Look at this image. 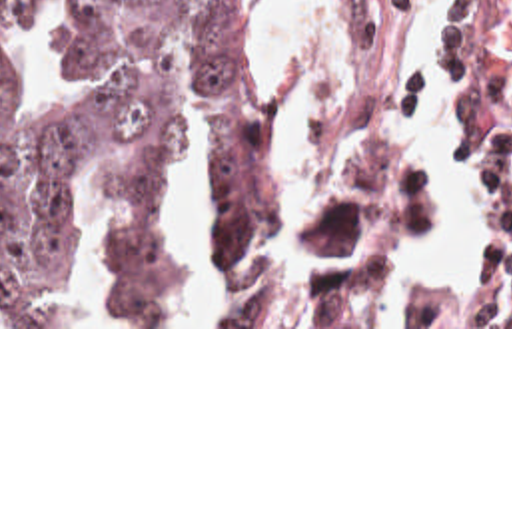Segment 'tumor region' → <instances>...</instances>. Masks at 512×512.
Instances as JSON below:
<instances>
[{
    "label": "tumor region",
    "instance_id": "e687c5a6",
    "mask_svg": "<svg viewBox=\"0 0 512 512\" xmlns=\"http://www.w3.org/2000/svg\"><path fill=\"white\" fill-rule=\"evenodd\" d=\"M40 0H0V325H62V257L76 229L74 177L84 155L112 143L98 175L114 185L162 181L180 151L176 48L218 117L214 257L226 261L273 219L277 201L257 161V69L241 0H80L76 51L90 89L46 103L18 85L14 36ZM383 115V113H381ZM389 119L387 115H383ZM311 139L317 157L367 141L369 157L305 227L311 253L353 255L391 235L413 155V131ZM108 325H168L162 307V185L116 219ZM391 253V255H393ZM383 263L315 285L305 325H365L389 273ZM232 325H261L245 303Z\"/></svg>",
    "mask_w": 512,
    "mask_h": 512
}]
</instances>
